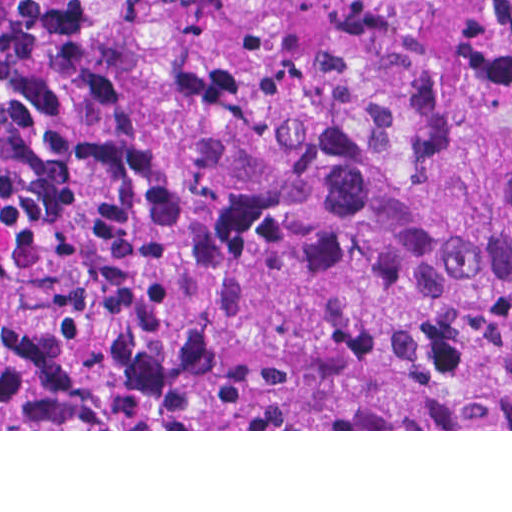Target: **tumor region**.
I'll list each match as a JSON object with an SVG mask.
<instances>
[{"mask_svg": "<svg viewBox=\"0 0 512 512\" xmlns=\"http://www.w3.org/2000/svg\"><path fill=\"white\" fill-rule=\"evenodd\" d=\"M0 372L56 430L512 429V0H0Z\"/></svg>", "mask_w": 512, "mask_h": 512, "instance_id": "e687c5a6", "label": "tumor region"}]
</instances>
